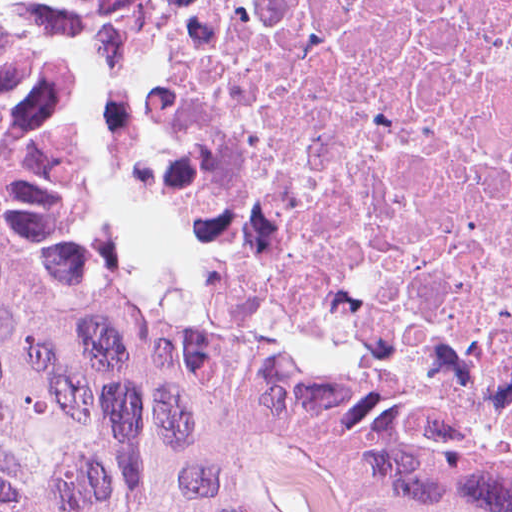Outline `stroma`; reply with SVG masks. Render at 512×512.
Returning <instances> with one entry per match:
<instances>
[{
	"mask_svg": "<svg viewBox=\"0 0 512 512\" xmlns=\"http://www.w3.org/2000/svg\"><path fill=\"white\" fill-rule=\"evenodd\" d=\"M141 16L142 11L119 63L105 71H76L65 63L60 95V248L67 285L113 299L167 332L209 339L253 357L300 385L340 393L378 417L417 425L457 449L485 455L336 382L278 358L234 348L219 333L190 281L137 250L106 205L99 126Z\"/></svg>",
	"mask_w": 512,
	"mask_h": 512,
	"instance_id": "1",
	"label": "stroma"
}]
</instances>
